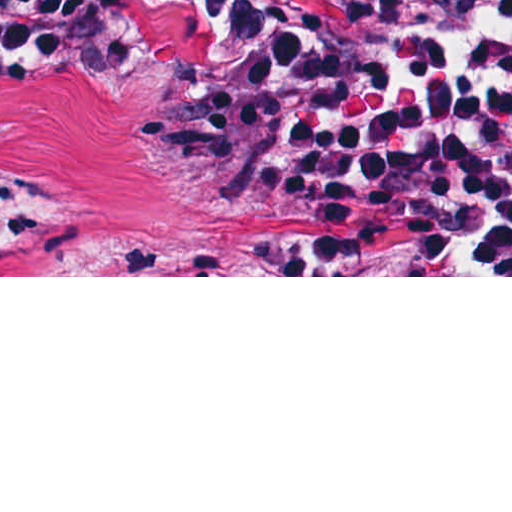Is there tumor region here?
Masks as SVG:
<instances>
[{"label":"tumor region","instance_id":"obj_1","mask_svg":"<svg viewBox=\"0 0 512 512\" xmlns=\"http://www.w3.org/2000/svg\"><path fill=\"white\" fill-rule=\"evenodd\" d=\"M269 83L267 72L135 55L94 82L0 60V184L33 235L0 275H227L210 236L153 220L284 242L350 275H439L424 251L301 227L206 174L196 135L261 103Z\"/></svg>","mask_w":512,"mask_h":512}]
</instances>
